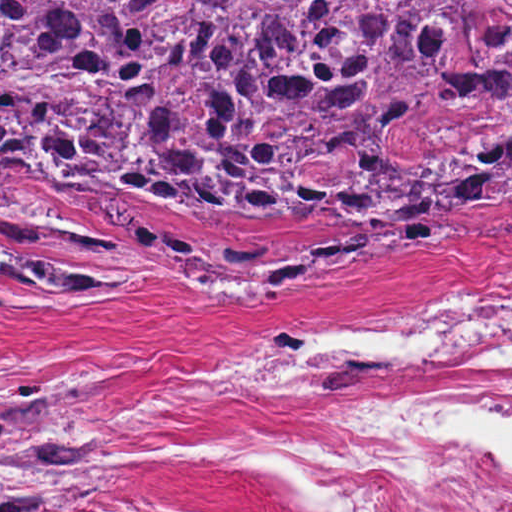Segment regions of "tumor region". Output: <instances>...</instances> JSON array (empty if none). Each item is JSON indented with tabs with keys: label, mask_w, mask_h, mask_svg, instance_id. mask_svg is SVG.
<instances>
[{
	"label": "tumor region",
	"mask_w": 512,
	"mask_h": 512,
	"mask_svg": "<svg viewBox=\"0 0 512 512\" xmlns=\"http://www.w3.org/2000/svg\"><path fill=\"white\" fill-rule=\"evenodd\" d=\"M37 170L253 225L512 198V0H0V199ZM120 484L85 405L0 378V512Z\"/></svg>",
	"instance_id": "obj_1"
}]
</instances>
